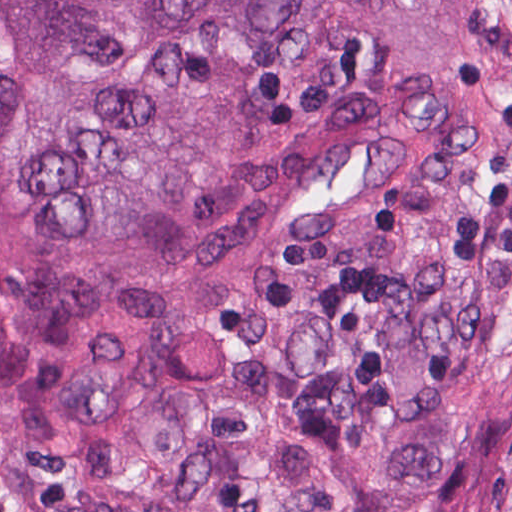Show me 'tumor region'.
I'll return each instance as SVG.
<instances>
[{
  "label": "tumor region",
  "instance_id": "obj_1",
  "mask_svg": "<svg viewBox=\"0 0 512 512\" xmlns=\"http://www.w3.org/2000/svg\"><path fill=\"white\" fill-rule=\"evenodd\" d=\"M395 0H0V512H268ZM288 512H512V0H400Z\"/></svg>",
  "mask_w": 512,
  "mask_h": 512
}]
</instances>
